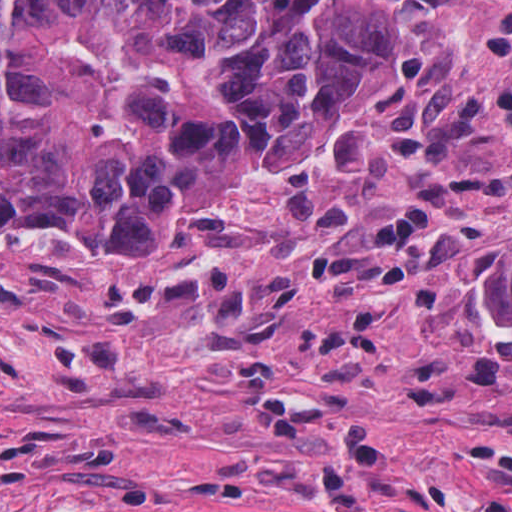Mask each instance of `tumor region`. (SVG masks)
I'll use <instances>...</instances> for the list:
<instances>
[{
    "label": "tumor region",
    "instance_id": "obj_1",
    "mask_svg": "<svg viewBox=\"0 0 512 512\" xmlns=\"http://www.w3.org/2000/svg\"><path fill=\"white\" fill-rule=\"evenodd\" d=\"M386 31L365 0H0V240L201 256L254 186L339 151L387 91Z\"/></svg>",
    "mask_w": 512,
    "mask_h": 512
}]
</instances>
